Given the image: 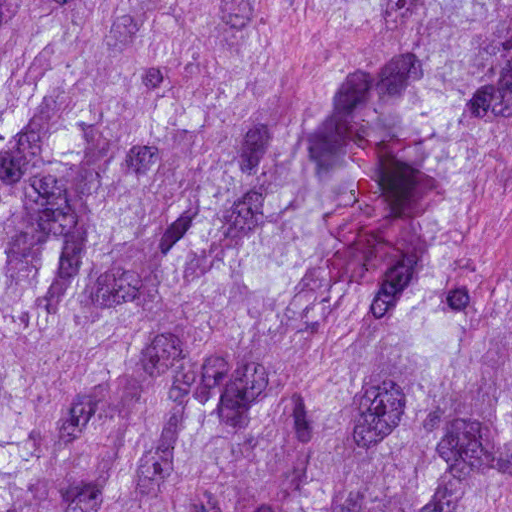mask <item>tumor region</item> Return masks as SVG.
Segmentation results:
<instances>
[{"label":"tumor region","instance_id":"e687c5a6","mask_svg":"<svg viewBox=\"0 0 512 512\" xmlns=\"http://www.w3.org/2000/svg\"><path fill=\"white\" fill-rule=\"evenodd\" d=\"M0 512H512V0H0Z\"/></svg>","mask_w":512,"mask_h":512}]
</instances>
